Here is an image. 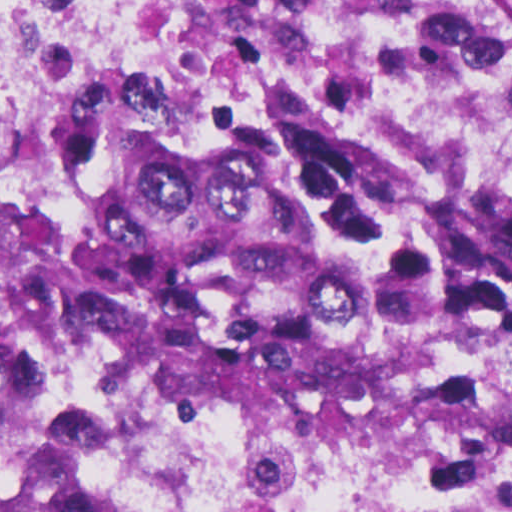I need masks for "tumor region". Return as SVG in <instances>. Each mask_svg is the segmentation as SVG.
I'll return each mask as SVG.
<instances>
[{"label": "tumor region", "instance_id": "tumor-region-1", "mask_svg": "<svg viewBox=\"0 0 512 512\" xmlns=\"http://www.w3.org/2000/svg\"><path fill=\"white\" fill-rule=\"evenodd\" d=\"M39 16L81 57L0 189V359L53 330L452 437L512 292V45L481 0H0V43ZM0 512L85 511L0 434Z\"/></svg>", "mask_w": 512, "mask_h": 512}]
</instances>
